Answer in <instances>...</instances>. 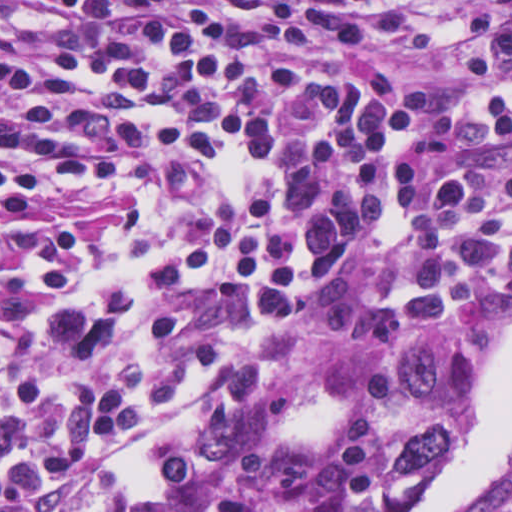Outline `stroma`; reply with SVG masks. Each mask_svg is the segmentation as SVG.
<instances>
[{
	"mask_svg": "<svg viewBox=\"0 0 512 512\" xmlns=\"http://www.w3.org/2000/svg\"><path fill=\"white\" fill-rule=\"evenodd\" d=\"M441 20L463 16L475 5L507 4L512 0H417ZM64 32L0 4V44L15 48L56 43ZM512 106V87L508 91ZM512 169V144L497 155ZM244 166L228 158L212 167L190 194L184 213L160 208L155 196L134 181L122 157L112 179L99 189L66 192L47 201L44 231L86 230L93 235V250L84 280L68 289L50 292L29 283L18 268L9 267L27 298V311L0 318V334L62 304L103 286L118 283L141 269L160 251L180 243L224 217L244 194ZM512 328V297L499 302L493 313L481 315L454 329L436 331L451 340L460 354V412L450 439L464 422L481 380L494 340ZM392 348L372 347L354 340L331 325L308 327L305 347L268 372V385L255 418L267 448L291 454L302 439L319 438L332 424V411L347 378L362 367H375L389 375ZM400 421L397 404V425ZM397 426L388 434L378 456L376 489L380 496L413 505L417 489L388 494L382 466ZM512 493V454L492 492L468 512H493Z\"/></svg>",
	"mask_w": 512,
	"mask_h": 512,
	"instance_id": "stroma-1",
	"label": "stroma"
}]
</instances>
